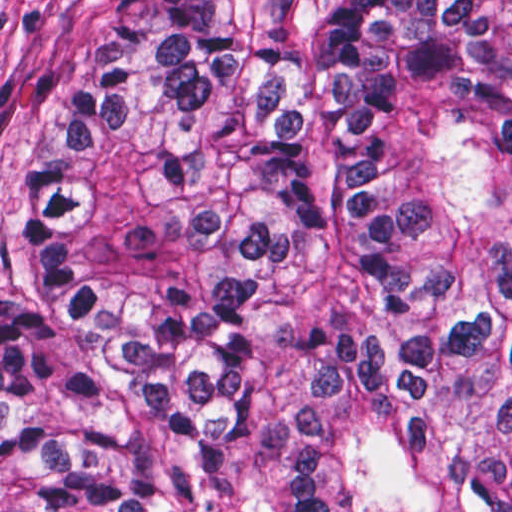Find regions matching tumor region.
Returning a JSON list of instances; mask_svg holds the SVG:
<instances>
[{"label":"tumor region","instance_id":"e687c5a6","mask_svg":"<svg viewBox=\"0 0 512 512\" xmlns=\"http://www.w3.org/2000/svg\"><path fill=\"white\" fill-rule=\"evenodd\" d=\"M0 512H512V0H145L0 290Z\"/></svg>","mask_w":512,"mask_h":512}]
</instances>
